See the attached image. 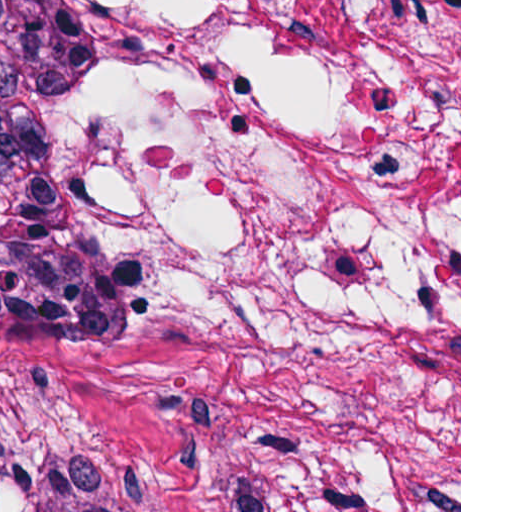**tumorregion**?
Masks as SVG:
<instances>
[{
    "label": "tumor region",
    "mask_w": 512,
    "mask_h": 512,
    "mask_svg": "<svg viewBox=\"0 0 512 512\" xmlns=\"http://www.w3.org/2000/svg\"><path fill=\"white\" fill-rule=\"evenodd\" d=\"M109 147L66 0H0V373L72 421L98 372Z\"/></svg>",
    "instance_id": "e687c5a6"
}]
</instances>
